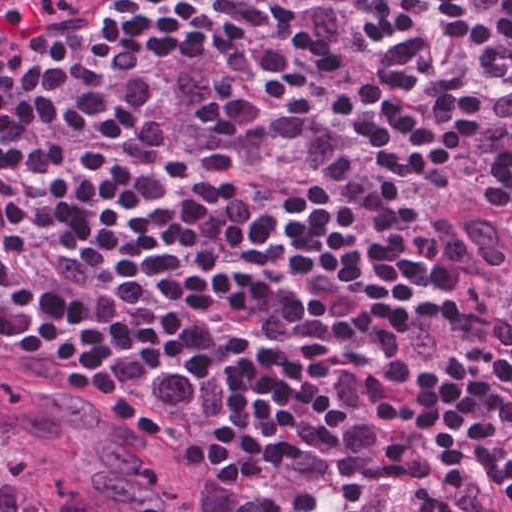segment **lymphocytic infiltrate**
Listing matches in <instances>:
<instances>
[{
  "label": "lymphocytic infiltrate",
  "mask_w": 512,
  "mask_h": 512,
  "mask_svg": "<svg viewBox=\"0 0 512 512\" xmlns=\"http://www.w3.org/2000/svg\"><path fill=\"white\" fill-rule=\"evenodd\" d=\"M144 1L0 54V366L126 431L199 362L226 399L170 470L257 512H512V293L419 218L470 195L512 256V0Z\"/></svg>",
  "instance_id": "lymphocytic-infiltrate-1"
}]
</instances>
